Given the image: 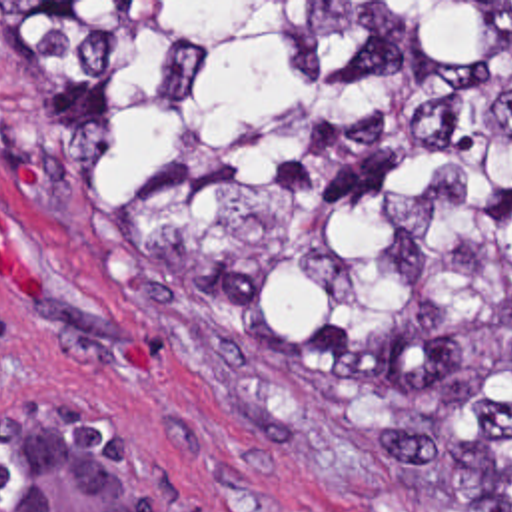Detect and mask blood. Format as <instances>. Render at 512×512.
<instances>
[{
    "mask_svg": "<svg viewBox=\"0 0 512 512\" xmlns=\"http://www.w3.org/2000/svg\"><path fill=\"white\" fill-rule=\"evenodd\" d=\"M14 180L32 182V166L16 164ZM0 276L6 277L16 287L18 293H36V277L26 270L18 254V240L10 230L8 222L2 218V214H0ZM120 355L128 367H148V351L138 347L136 343L128 345Z\"/></svg>",
    "mask_w": 512,
    "mask_h": 512,
    "instance_id": "1",
    "label": "blood"
}]
</instances>
